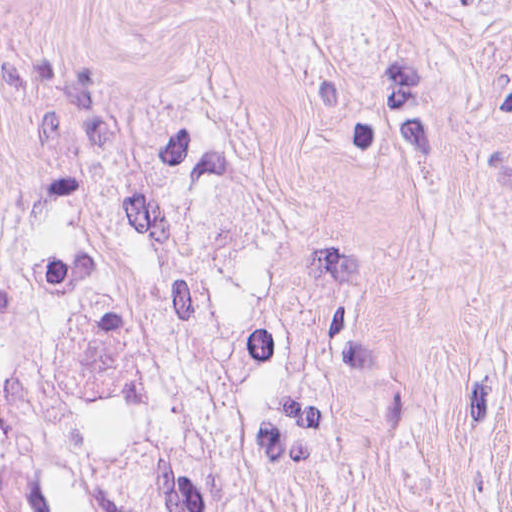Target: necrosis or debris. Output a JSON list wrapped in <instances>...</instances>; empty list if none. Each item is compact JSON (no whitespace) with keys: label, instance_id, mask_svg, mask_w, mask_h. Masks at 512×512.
<instances>
[{"label":"necrosis or debris","instance_id":"4bbe7bcc","mask_svg":"<svg viewBox=\"0 0 512 512\" xmlns=\"http://www.w3.org/2000/svg\"><path fill=\"white\" fill-rule=\"evenodd\" d=\"M0 512H305L265 204L168 137L0 209Z\"/></svg>","mask_w":512,"mask_h":512}]
</instances>
